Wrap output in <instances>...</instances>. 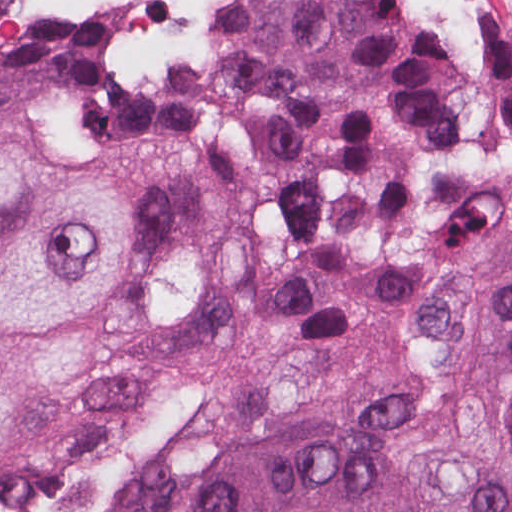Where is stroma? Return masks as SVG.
I'll use <instances>...</instances> for the list:
<instances>
[{
    "instance_id": "1",
    "label": "stroma",
    "mask_w": 512,
    "mask_h": 512,
    "mask_svg": "<svg viewBox=\"0 0 512 512\" xmlns=\"http://www.w3.org/2000/svg\"><path fill=\"white\" fill-rule=\"evenodd\" d=\"M441 47L512 40V0H385ZM114 14L111 0H0V35ZM132 72L114 43L104 71ZM56 147L180 149L223 207L174 229L78 332L84 368L22 391L0 445V512H180L228 461L287 436H361L417 487L467 475L502 440L490 352L512 249V158L453 157L409 220L297 208L262 230L217 144L59 128L0 105Z\"/></svg>"
}]
</instances>
